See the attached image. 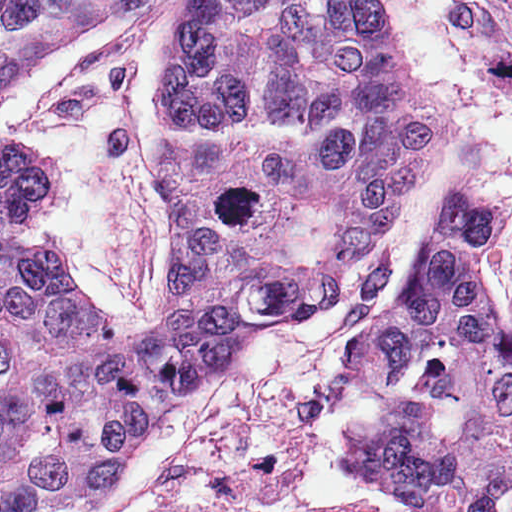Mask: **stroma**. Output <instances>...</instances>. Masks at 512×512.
Here are the masks:
<instances>
[{"label":"stroma","mask_w":512,"mask_h":512,"mask_svg":"<svg viewBox=\"0 0 512 512\" xmlns=\"http://www.w3.org/2000/svg\"><path fill=\"white\" fill-rule=\"evenodd\" d=\"M198 1L160 0L134 29L56 53L2 113L0 152L55 170L51 203L33 218L35 236H54L46 255L100 308L136 323H158L185 274V225L162 191L147 111L163 41ZM391 1L430 102L457 121L444 161L324 310L252 342L162 415L102 512H363L349 495L307 499L311 429L336 404L378 411L346 364L350 343L411 280L457 189L497 213L486 254L512 334V0Z\"/></svg>","instance_id":"stroma-1"}]
</instances>
